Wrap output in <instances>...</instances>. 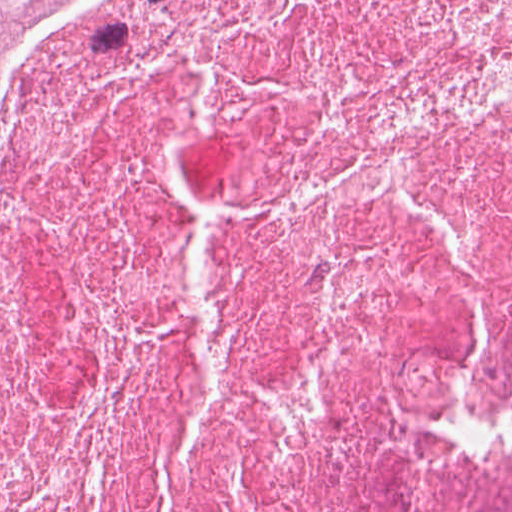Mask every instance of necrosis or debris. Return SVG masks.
<instances>
[{
  "instance_id": "4bbe7bcc",
  "label": "necrosis or debris",
  "mask_w": 512,
  "mask_h": 512,
  "mask_svg": "<svg viewBox=\"0 0 512 512\" xmlns=\"http://www.w3.org/2000/svg\"><path fill=\"white\" fill-rule=\"evenodd\" d=\"M0 512H512V0H59Z\"/></svg>"
}]
</instances>
